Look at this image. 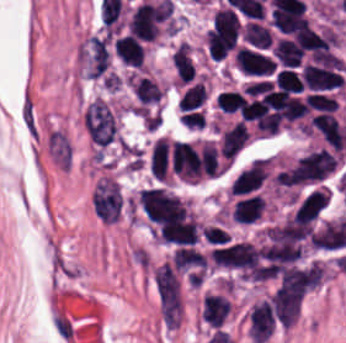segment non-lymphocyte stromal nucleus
I'll list each match as a JSON object with an SVG mask.
<instances>
[{"mask_svg": "<svg viewBox=\"0 0 346 343\" xmlns=\"http://www.w3.org/2000/svg\"><path fill=\"white\" fill-rule=\"evenodd\" d=\"M90 204L93 212L102 223L108 224L119 221L122 197L115 177L103 173L96 178Z\"/></svg>", "mask_w": 346, "mask_h": 343, "instance_id": "non-lymphocyte-stromal-nucleus-1", "label": "non-lymphocyte stromal nucleus"}]
</instances>
